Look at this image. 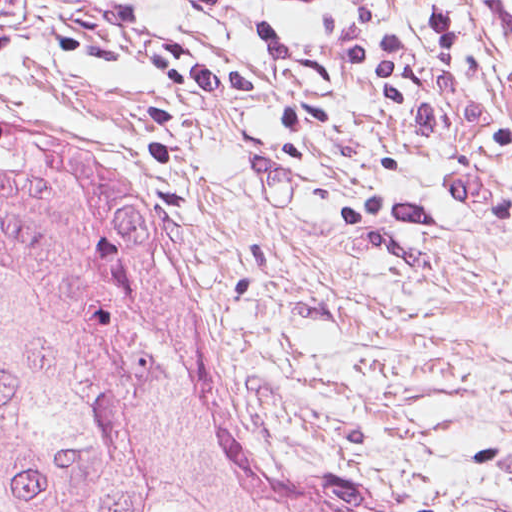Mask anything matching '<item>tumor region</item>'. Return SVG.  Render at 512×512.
I'll return each mask as SVG.
<instances>
[{"mask_svg": "<svg viewBox=\"0 0 512 512\" xmlns=\"http://www.w3.org/2000/svg\"><path fill=\"white\" fill-rule=\"evenodd\" d=\"M0 512H366L225 388L159 280L0 247Z\"/></svg>", "mask_w": 512, "mask_h": 512, "instance_id": "tumor-region-1", "label": "tumor region"}]
</instances>
